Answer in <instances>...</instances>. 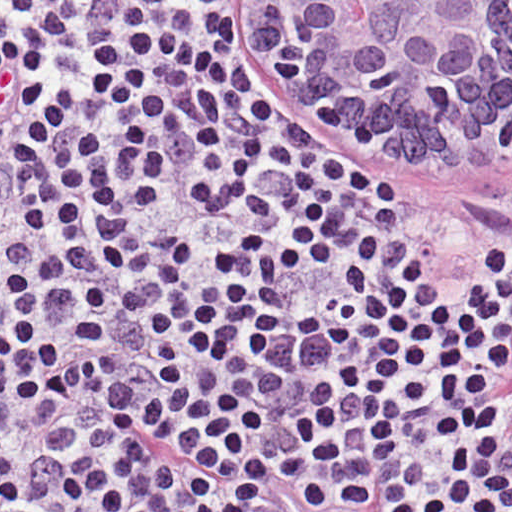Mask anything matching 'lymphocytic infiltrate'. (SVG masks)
I'll use <instances>...</instances> for the list:
<instances>
[{
	"instance_id": "obj_1",
	"label": "lymphocytic infiltrate",
	"mask_w": 512,
	"mask_h": 512,
	"mask_svg": "<svg viewBox=\"0 0 512 512\" xmlns=\"http://www.w3.org/2000/svg\"><path fill=\"white\" fill-rule=\"evenodd\" d=\"M233 5L0 1V512H273L210 418L297 387L498 445L512 512V243L387 217L246 93Z\"/></svg>"
}]
</instances>
